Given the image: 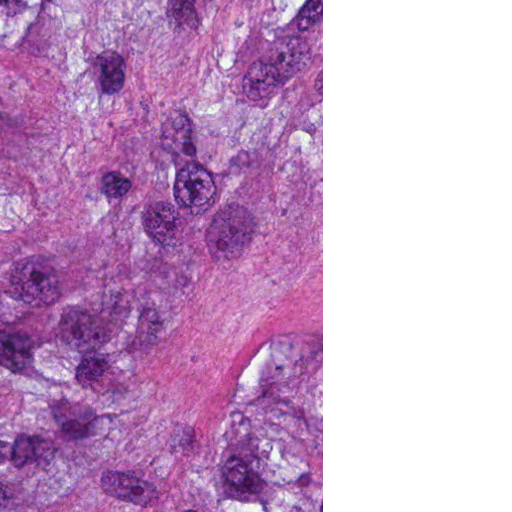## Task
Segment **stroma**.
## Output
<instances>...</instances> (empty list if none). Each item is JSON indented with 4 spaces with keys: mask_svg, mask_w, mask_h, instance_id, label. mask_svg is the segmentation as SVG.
<instances>
[{
    "mask_svg": "<svg viewBox=\"0 0 512 512\" xmlns=\"http://www.w3.org/2000/svg\"><path fill=\"white\" fill-rule=\"evenodd\" d=\"M161 512H323V0H161Z\"/></svg>",
    "mask_w": 512,
    "mask_h": 512,
    "instance_id": "stroma-1",
    "label": "stroma"
}]
</instances>
